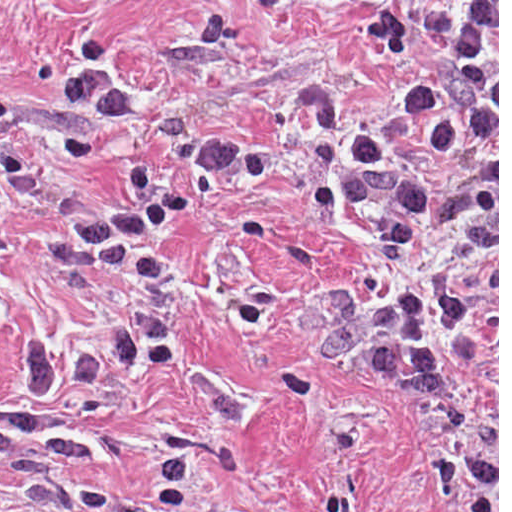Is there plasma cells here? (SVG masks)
Instances as JSON below:
<instances>
[{"label": "plasma cells", "instance_id": "obj_1", "mask_svg": "<svg viewBox=\"0 0 512 512\" xmlns=\"http://www.w3.org/2000/svg\"><path fill=\"white\" fill-rule=\"evenodd\" d=\"M435 66L407 93L404 109L420 115L436 151L446 155L460 142L459 116L470 118L474 148L482 169L458 197L424 192L398 147L364 133L347 138L342 96L327 84L302 91V106L314 127L317 161L332 172V186L342 208L376 206L397 191L385 267L394 252L419 226L460 221L464 243L430 282L404 296L383 298V337L395 364L419 387L455 391L442 349L429 325L459 326L471 311L445 283L443 273L470 260L484 280V348L497 386V1H444ZM60 105L82 108L114 126L131 123L132 113L104 70L69 75L58 94ZM5 251V204L0 196V258ZM170 337L156 319L130 317L97 346L60 348L47 341L21 339L8 352L21 388L50 399L61 389H101L136 371L144 361L162 357ZM68 463L99 454L90 434L39 419L23 410H0V463L12 465L29 499L48 512H176L184 498V459H163L153 477L151 495L122 499L103 492L53 487L27 458Z\"/></svg>", "mask_w": 512, "mask_h": 512}]
</instances>
